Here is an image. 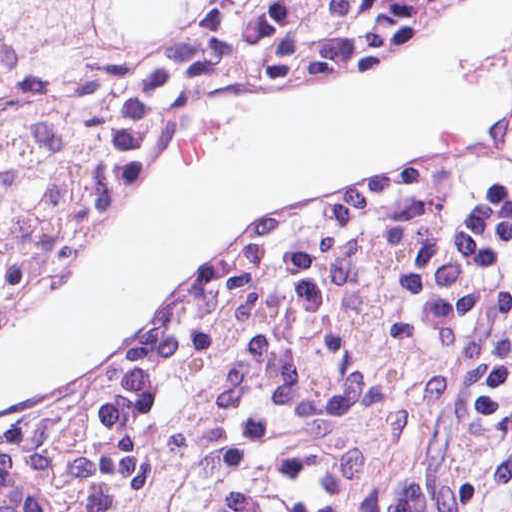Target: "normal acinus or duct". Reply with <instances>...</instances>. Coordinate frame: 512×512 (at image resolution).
Returning a JSON list of instances; mask_svg holds the SVG:
<instances>
[{
    "instance_id": "1",
    "label": "normal acinus or duct",
    "mask_w": 512,
    "mask_h": 512,
    "mask_svg": "<svg viewBox=\"0 0 512 512\" xmlns=\"http://www.w3.org/2000/svg\"><path fill=\"white\" fill-rule=\"evenodd\" d=\"M0 512H43L24 474L1 450Z\"/></svg>"
}]
</instances>
